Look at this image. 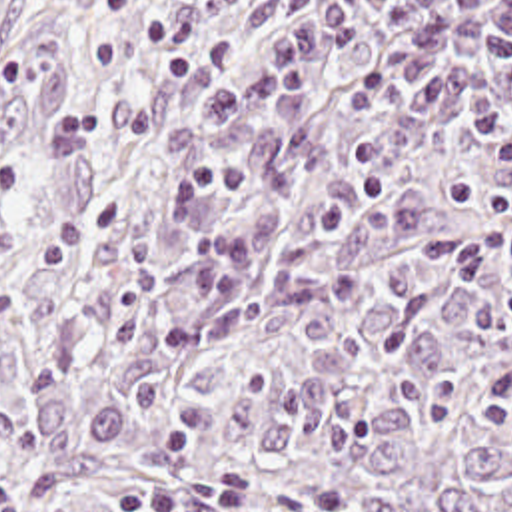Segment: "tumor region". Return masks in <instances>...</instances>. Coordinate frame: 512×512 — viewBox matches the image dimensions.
<instances>
[{"instance_id":"1","label":"tumor region","mask_w":512,"mask_h":512,"mask_svg":"<svg viewBox=\"0 0 512 512\" xmlns=\"http://www.w3.org/2000/svg\"><path fill=\"white\" fill-rule=\"evenodd\" d=\"M334 0H66L0 75V512H512V63L360 123L404 45L354 43L200 143L232 245L370 185L384 207L258 267L174 261L182 111Z\"/></svg>"}]
</instances>
